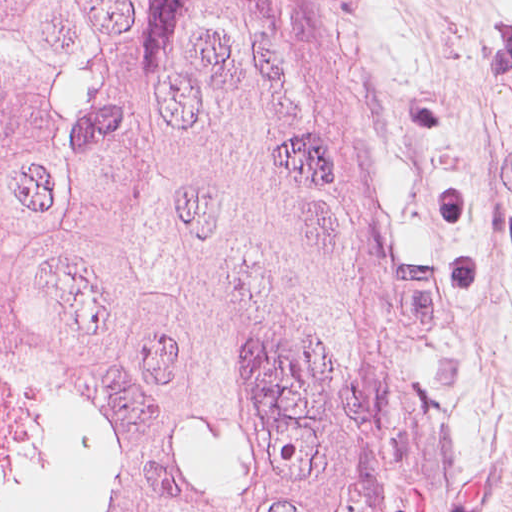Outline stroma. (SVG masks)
<instances>
[{
    "label": "stroma",
    "mask_w": 512,
    "mask_h": 512,
    "mask_svg": "<svg viewBox=\"0 0 512 512\" xmlns=\"http://www.w3.org/2000/svg\"><path fill=\"white\" fill-rule=\"evenodd\" d=\"M376 512H423L512 95V0H263Z\"/></svg>",
    "instance_id": "obj_1"
}]
</instances>
